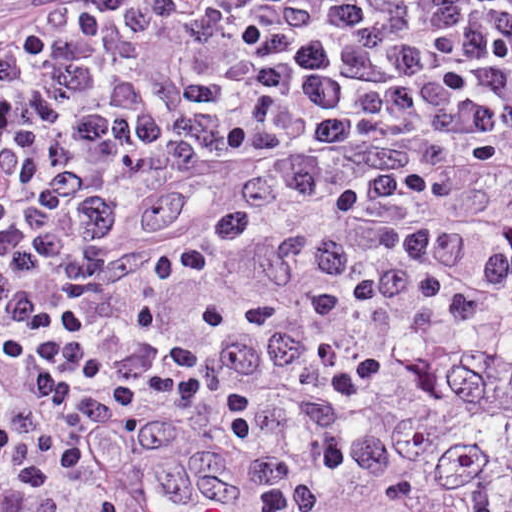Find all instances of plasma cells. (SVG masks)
<instances>
[{
  "mask_svg": "<svg viewBox=\"0 0 512 512\" xmlns=\"http://www.w3.org/2000/svg\"><path fill=\"white\" fill-rule=\"evenodd\" d=\"M510 253L512 0H0L13 512Z\"/></svg>",
  "mask_w": 512,
  "mask_h": 512,
  "instance_id": "9512152a",
  "label": "plasma cells"
}]
</instances>
